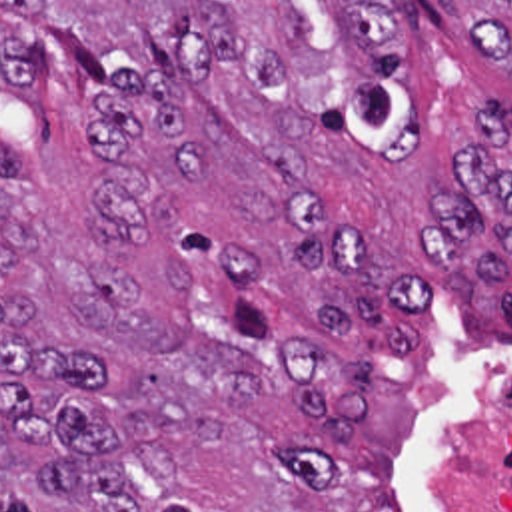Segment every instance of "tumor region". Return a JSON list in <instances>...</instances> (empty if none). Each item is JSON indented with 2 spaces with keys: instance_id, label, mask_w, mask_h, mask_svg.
<instances>
[{
  "instance_id": "e687c5a6",
  "label": "tumor region",
  "mask_w": 512,
  "mask_h": 512,
  "mask_svg": "<svg viewBox=\"0 0 512 512\" xmlns=\"http://www.w3.org/2000/svg\"><path fill=\"white\" fill-rule=\"evenodd\" d=\"M62 54L26 82L0 22V512H406L392 455L408 393L362 357L322 353L252 306L256 264L172 222L164 192L196 188L210 154L162 76L112 72L102 36L50 0H0ZM473 54L512 80V0H439ZM420 14L408 0H170L190 82L224 62L264 92V146L312 184L318 124L384 168L424 148L410 84ZM512 112L483 104L449 160L465 190L434 198L422 258L445 300L509 268ZM98 212V222H96ZM306 272L346 268L330 329L364 351H414L406 312L432 278H386L376 236L310 212Z\"/></svg>"
}]
</instances>
